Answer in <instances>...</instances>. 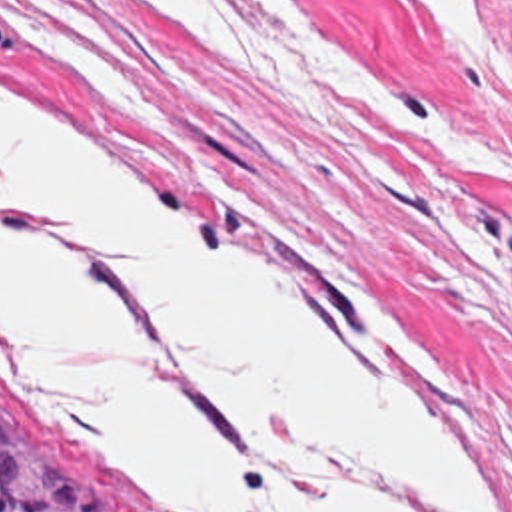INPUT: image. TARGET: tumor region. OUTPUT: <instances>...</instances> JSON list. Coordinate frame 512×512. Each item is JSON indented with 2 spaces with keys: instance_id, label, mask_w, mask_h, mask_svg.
<instances>
[{
  "instance_id": "1",
  "label": "tumor region",
  "mask_w": 512,
  "mask_h": 512,
  "mask_svg": "<svg viewBox=\"0 0 512 512\" xmlns=\"http://www.w3.org/2000/svg\"><path fill=\"white\" fill-rule=\"evenodd\" d=\"M0 512H116L75 452L1 394Z\"/></svg>"
}]
</instances>
